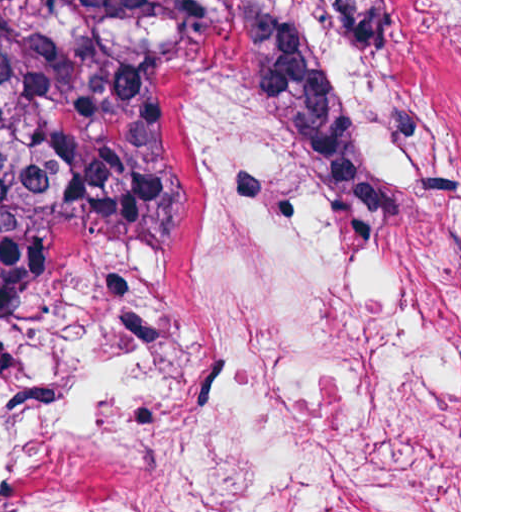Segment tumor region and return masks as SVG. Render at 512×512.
Masks as SVG:
<instances>
[{
	"label": "tumor region",
	"mask_w": 512,
	"mask_h": 512,
	"mask_svg": "<svg viewBox=\"0 0 512 512\" xmlns=\"http://www.w3.org/2000/svg\"><path fill=\"white\" fill-rule=\"evenodd\" d=\"M253 93L302 142L353 235L393 184L425 236L455 166L445 107L395 0H0V322L51 278L49 240L89 227L171 248L170 169L239 47Z\"/></svg>",
	"instance_id": "obj_1"
}]
</instances>
